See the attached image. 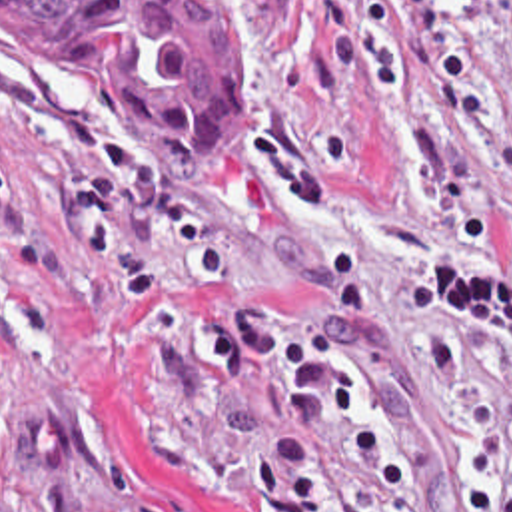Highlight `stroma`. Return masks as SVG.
<instances>
[{"label":"stroma","instance_id":"obj_1","mask_svg":"<svg viewBox=\"0 0 512 512\" xmlns=\"http://www.w3.org/2000/svg\"><path fill=\"white\" fill-rule=\"evenodd\" d=\"M202 2L243 58V167L212 199L166 193L124 98L0 18V512H253L237 469L273 391L206 375L190 323L255 293L275 325L311 327L331 229L365 261L363 407L407 483L387 511L465 512L467 419L421 341H449L469 387L512 407V329L455 331L405 281L439 257L479 283L503 273V245L461 237L447 207L512 213V0L417 2L469 50L479 117L401 44L395 94L329 68L323 32L347 0ZM44 407L58 463L24 441ZM311 469V512L367 511L365 453L317 427Z\"/></svg>","mask_w":512,"mask_h":512}]
</instances>
